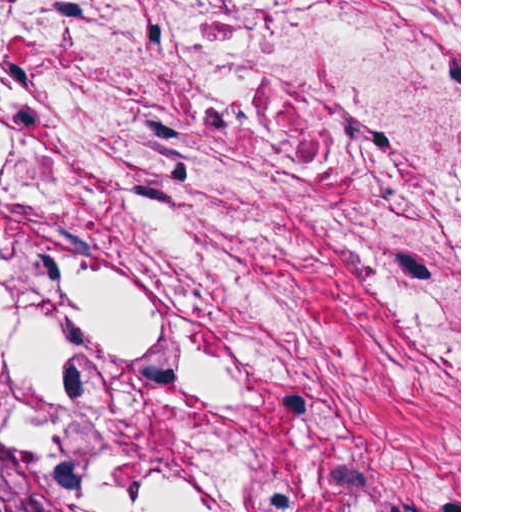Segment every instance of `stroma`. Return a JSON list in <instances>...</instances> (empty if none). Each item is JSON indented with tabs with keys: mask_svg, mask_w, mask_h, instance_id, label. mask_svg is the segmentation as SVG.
<instances>
[{
	"mask_svg": "<svg viewBox=\"0 0 512 512\" xmlns=\"http://www.w3.org/2000/svg\"><path fill=\"white\" fill-rule=\"evenodd\" d=\"M0 408L65 512H461V0H0Z\"/></svg>",
	"mask_w": 512,
	"mask_h": 512,
	"instance_id": "1",
	"label": "stroma"
}]
</instances>
